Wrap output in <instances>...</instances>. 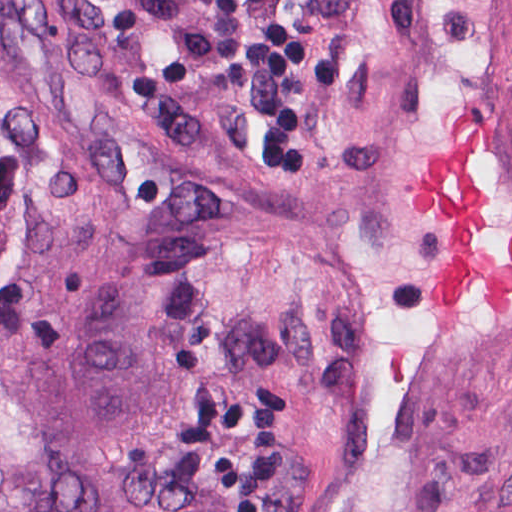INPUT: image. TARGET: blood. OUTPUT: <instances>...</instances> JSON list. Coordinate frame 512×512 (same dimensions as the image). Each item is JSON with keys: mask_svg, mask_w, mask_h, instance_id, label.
I'll return each mask as SVG.
<instances>
[{"mask_svg": "<svg viewBox=\"0 0 512 512\" xmlns=\"http://www.w3.org/2000/svg\"><path fill=\"white\" fill-rule=\"evenodd\" d=\"M476 120L454 121L440 153L422 156L414 201L439 208L449 225L446 241L430 276L434 302L445 312L459 309L470 285L494 315H510L512 252L505 264L486 251L476 236L490 232L488 202L476 179Z\"/></svg>", "mask_w": 512, "mask_h": 512, "instance_id": "1", "label": "blood"}]
</instances>
